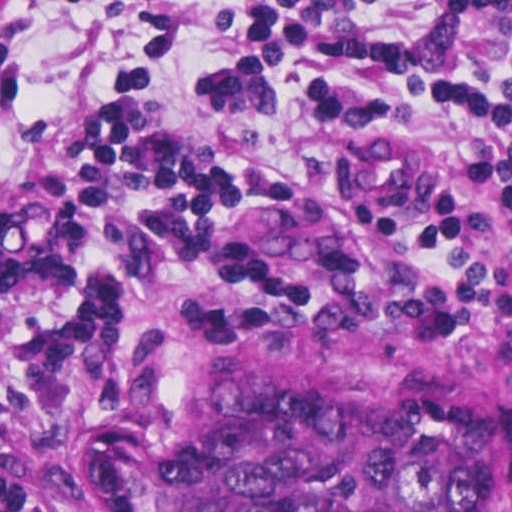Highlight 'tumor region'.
<instances>
[{
  "mask_svg": "<svg viewBox=\"0 0 512 512\" xmlns=\"http://www.w3.org/2000/svg\"><path fill=\"white\" fill-rule=\"evenodd\" d=\"M501 420L437 389L245 385L182 425L153 459L158 512H477Z\"/></svg>",
  "mask_w": 512,
  "mask_h": 512,
  "instance_id": "1",
  "label": "tumor region"
}]
</instances>
